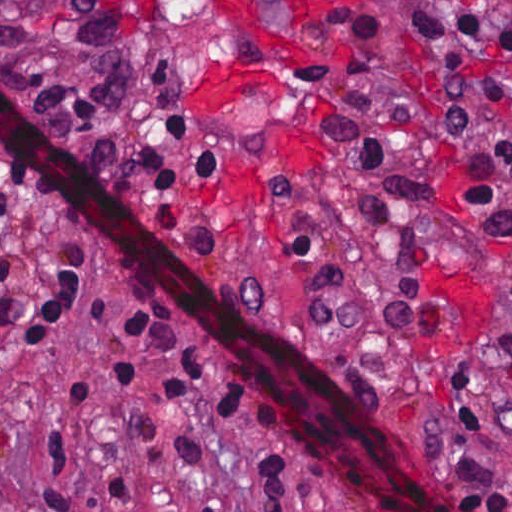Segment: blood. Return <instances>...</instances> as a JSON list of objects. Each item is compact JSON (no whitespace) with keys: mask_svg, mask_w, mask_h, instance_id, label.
Here are the masks:
<instances>
[{"mask_svg":"<svg viewBox=\"0 0 512 512\" xmlns=\"http://www.w3.org/2000/svg\"><path fill=\"white\" fill-rule=\"evenodd\" d=\"M292 12L315 14L344 9L356 0H284ZM223 21L260 42L267 53L256 64H205L190 71L189 106L215 99L265 101L283 99V71L300 62L296 30L271 17L265 0H214Z\"/></svg>","mask_w":512,"mask_h":512,"instance_id":"1","label":"blood"}]
</instances>
